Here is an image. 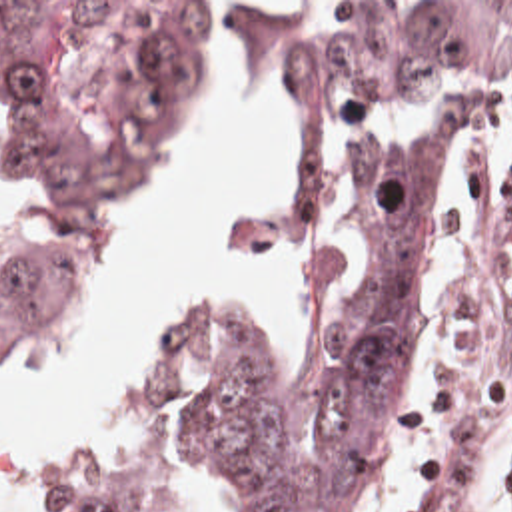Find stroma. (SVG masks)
I'll return each mask as SVG.
<instances>
[{
  "mask_svg": "<svg viewBox=\"0 0 512 512\" xmlns=\"http://www.w3.org/2000/svg\"><path fill=\"white\" fill-rule=\"evenodd\" d=\"M0 2H162L186 26L206 0ZM382 2L320 0L318 26ZM511 84L512 48L473 78L471 90L481 106L473 124L501 108ZM286 110L308 146L302 114L288 102ZM374 114L394 140L430 120L452 124L432 104H396ZM473 124L460 126L450 150V190L398 425L360 481L348 512H420V485L452 439L481 435L495 421H512V186L493 180L477 158L460 150ZM338 192L322 194L310 180V254ZM8 216L10 170L0 146V224Z\"/></svg>",
  "mask_w": 512,
  "mask_h": 512,
  "instance_id": "1",
  "label": "stroma"
}]
</instances>
